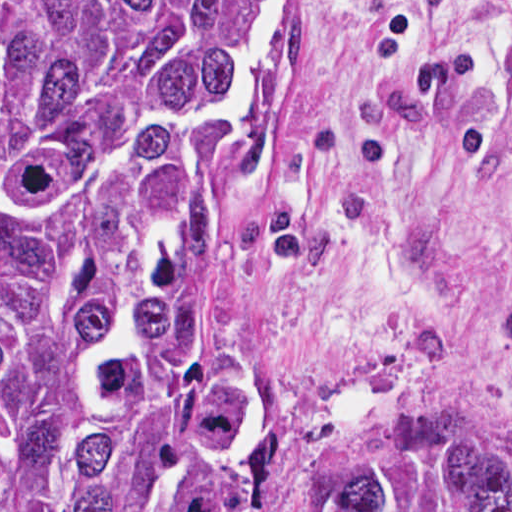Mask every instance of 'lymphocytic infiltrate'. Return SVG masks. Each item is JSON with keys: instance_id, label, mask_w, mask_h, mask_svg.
I'll return each mask as SVG.
<instances>
[{"instance_id": "lymphocytic-infiltrate-1", "label": "lymphocytic infiltrate", "mask_w": 512, "mask_h": 512, "mask_svg": "<svg viewBox=\"0 0 512 512\" xmlns=\"http://www.w3.org/2000/svg\"><path fill=\"white\" fill-rule=\"evenodd\" d=\"M383 26L388 49L394 55L414 52L419 36L418 25L404 16L396 0H372Z\"/></svg>"}]
</instances>
